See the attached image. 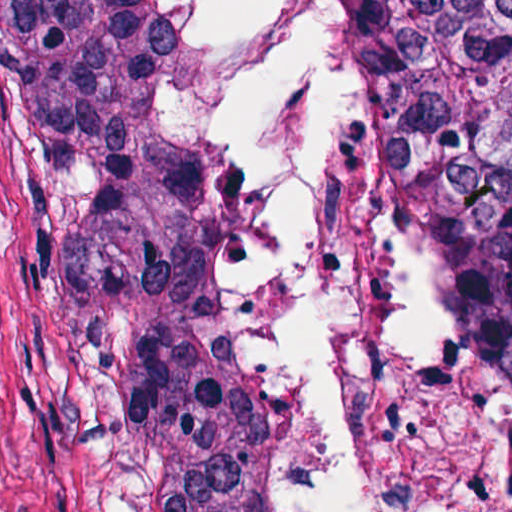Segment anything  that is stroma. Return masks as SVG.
<instances>
[{
  "label": "stroma",
  "instance_id": "obj_1",
  "mask_svg": "<svg viewBox=\"0 0 512 512\" xmlns=\"http://www.w3.org/2000/svg\"><path fill=\"white\" fill-rule=\"evenodd\" d=\"M180 1L0 0V512H169L142 416L112 252V59L176 38ZM372 143L392 178L348 12Z\"/></svg>",
  "mask_w": 512,
  "mask_h": 512
}]
</instances>
